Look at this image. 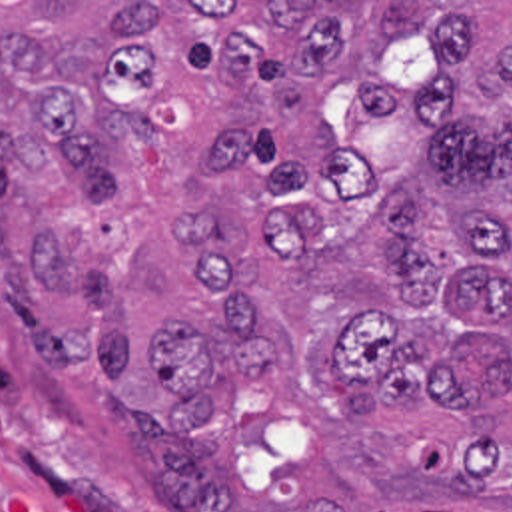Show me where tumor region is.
<instances>
[{"mask_svg": "<svg viewBox=\"0 0 512 512\" xmlns=\"http://www.w3.org/2000/svg\"><path fill=\"white\" fill-rule=\"evenodd\" d=\"M0 304L165 512H512V0H0Z\"/></svg>", "mask_w": 512, "mask_h": 512, "instance_id": "obj_1", "label": "tumor region"}]
</instances>
